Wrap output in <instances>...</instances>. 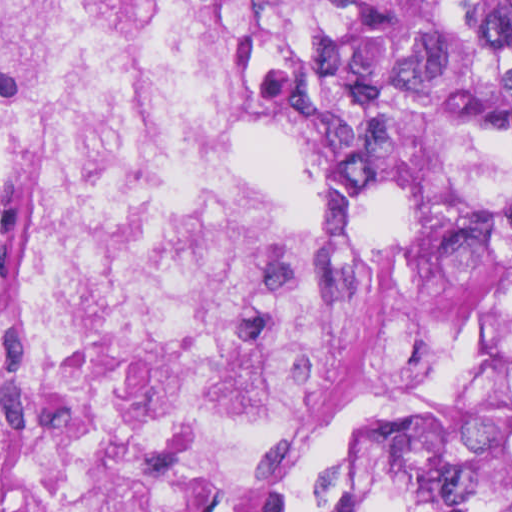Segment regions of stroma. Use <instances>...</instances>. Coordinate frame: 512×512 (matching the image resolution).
Returning a JSON list of instances; mask_svg holds the SVG:
<instances>
[{"mask_svg":"<svg viewBox=\"0 0 512 512\" xmlns=\"http://www.w3.org/2000/svg\"><path fill=\"white\" fill-rule=\"evenodd\" d=\"M243 50L240 120L224 135L232 162L267 209L319 191L355 195L377 216L430 213L504 250L508 280L464 343L401 384L305 472L282 512H413L447 458L512 415L509 197H379L339 180L286 142L263 106L228 0H214Z\"/></svg>","mask_w":512,"mask_h":512,"instance_id":"obj_1","label":"stroma"}]
</instances>
